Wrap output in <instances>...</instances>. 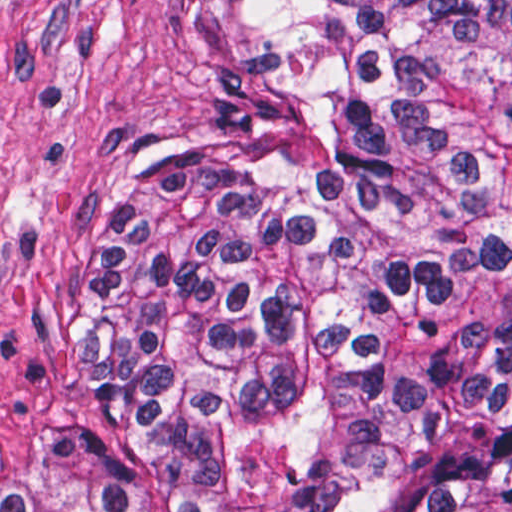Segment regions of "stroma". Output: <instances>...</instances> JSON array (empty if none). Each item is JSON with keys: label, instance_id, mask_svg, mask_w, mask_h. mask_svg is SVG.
Instances as JSON below:
<instances>
[{"label": "stroma", "instance_id": "obj_1", "mask_svg": "<svg viewBox=\"0 0 512 512\" xmlns=\"http://www.w3.org/2000/svg\"><path fill=\"white\" fill-rule=\"evenodd\" d=\"M300 62L244 0H0V449L62 417L95 189L145 134L290 145Z\"/></svg>", "mask_w": 512, "mask_h": 512}]
</instances>
